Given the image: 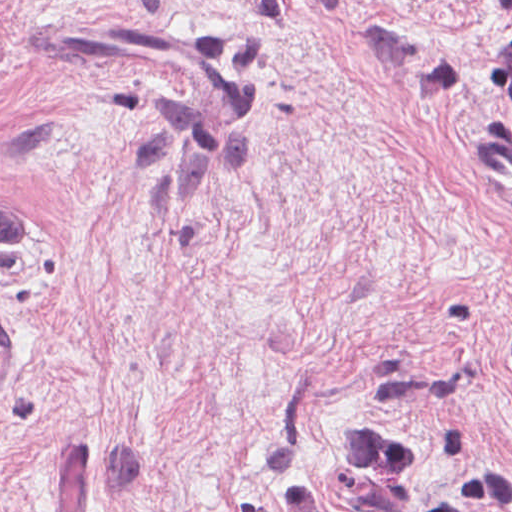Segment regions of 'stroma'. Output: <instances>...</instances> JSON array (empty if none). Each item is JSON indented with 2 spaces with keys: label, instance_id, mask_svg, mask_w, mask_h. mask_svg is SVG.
<instances>
[{
  "label": "stroma",
  "instance_id": "1",
  "mask_svg": "<svg viewBox=\"0 0 512 512\" xmlns=\"http://www.w3.org/2000/svg\"><path fill=\"white\" fill-rule=\"evenodd\" d=\"M493 0H0V512L349 510L364 424L512 477Z\"/></svg>",
  "mask_w": 512,
  "mask_h": 512
}]
</instances>
